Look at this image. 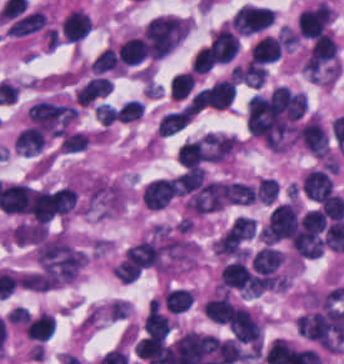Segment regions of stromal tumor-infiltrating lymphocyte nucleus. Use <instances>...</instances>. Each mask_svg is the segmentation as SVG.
Segmentation results:
<instances>
[{"label": "stromal tumor-infiltrating lymphocyte nucleus", "instance_id": "bc302bb0", "mask_svg": "<svg viewBox=\"0 0 344 364\" xmlns=\"http://www.w3.org/2000/svg\"><path fill=\"white\" fill-rule=\"evenodd\" d=\"M299 206L286 202L274 208L264 223L260 234L267 245L289 240L296 226Z\"/></svg>", "mask_w": 344, "mask_h": 364}, {"label": "stromal tumor-infiltrating lymphocyte nucleus", "instance_id": "52c7bb5b", "mask_svg": "<svg viewBox=\"0 0 344 364\" xmlns=\"http://www.w3.org/2000/svg\"><path fill=\"white\" fill-rule=\"evenodd\" d=\"M333 13L327 3L319 2L302 10L297 31L302 38H315L325 32Z\"/></svg>", "mask_w": 344, "mask_h": 364}, {"label": "stromal tumor-infiltrating lymphocyte nucleus", "instance_id": "3290ff9b", "mask_svg": "<svg viewBox=\"0 0 344 364\" xmlns=\"http://www.w3.org/2000/svg\"><path fill=\"white\" fill-rule=\"evenodd\" d=\"M220 286L242 294H255V284L250 268L243 260H235L223 265Z\"/></svg>", "mask_w": 344, "mask_h": 364}, {"label": "stromal tumor-infiltrating lymphocyte nucleus", "instance_id": "abfb95fc", "mask_svg": "<svg viewBox=\"0 0 344 364\" xmlns=\"http://www.w3.org/2000/svg\"><path fill=\"white\" fill-rule=\"evenodd\" d=\"M298 137L303 147L314 156L323 158L328 156V139L318 115H311L299 123Z\"/></svg>", "mask_w": 344, "mask_h": 364}, {"label": "stromal tumor-infiltrating lymphocyte nucleus", "instance_id": "9ea309e8", "mask_svg": "<svg viewBox=\"0 0 344 364\" xmlns=\"http://www.w3.org/2000/svg\"><path fill=\"white\" fill-rule=\"evenodd\" d=\"M233 339L242 344L260 345L261 325L248 311L236 307L229 323Z\"/></svg>", "mask_w": 344, "mask_h": 364}, {"label": "stromal tumor-infiltrating lymphocyte nucleus", "instance_id": "f3e2335f", "mask_svg": "<svg viewBox=\"0 0 344 364\" xmlns=\"http://www.w3.org/2000/svg\"><path fill=\"white\" fill-rule=\"evenodd\" d=\"M122 264L131 270L140 271L160 265V246L153 241H139L126 250Z\"/></svg>", "mask_w": 344, "mask_h": 364}, {"label": "stromal tumor-infiltrating lymphocyte nucleus", "instance_id": "4f13568d", "mask_svg": "<svg viewBox=\"0 0 344 364\" xmlns=\"http://www.w3.org/2000/svg\"><path fill=\"white\" fill-rule=\"evenodd\" d=\"M175 193L173 177L154 179L141 191L140 198L144 207L150 211H158L167 205Z\"/></svg>", "mask_w": 344, "mask_h": 364}, {"label": "stromal tumor-infiltrating lymphocyte nucleus", "instance_id": "2a367800", "mask_svg": "<svg viewBox=\"0 0 344 364\" xmlns=\"http://www.w3.org/2000/svg\"><path fill=\"white\" fill-rule=\"evenodd\" d=\"M256 232L253 217L237 216L219 237L223 250H236L249 241Z\"/></svg>", "mask_w": 344, "mask_h": 364}, {"label": "stromal tumor-infiltrating lymphocyte nucleus", "instance_id": "4803ca6d", "mask_svg": "<svg viewBox=\"0 0 344 364\" xmlns=\"http://www.w3.org/2000/svg\"><path fill=\"white\" fill-rule=\"evenodd\" d=\"M210 41L214 63H228L239 45L237 35L224 23L210 34Z\"/></svg>", "mask_w": 344, "mask_h": 364}, {"label": "stromal tumor-infiltrating lymphocyte nucleus", "instance_id": "4245b91a", "mask_svg": "<svg viewBox=\"0 0 344 364\" xmlns=\"http://www.w3.org/2000/svg\"><path fill=\"white\" fill-rule=\"evenodd\" d=\"M61 31L65 40L79 42L90 32V18L79 9H71L61 21Z\"/></svg>", "mask_w": 344, "mask_h": 364}, {"label": "stromal tumor-infiltrating lymphocyte nucleus", "instance_id": "4c9ddf68", "mask_svg": "<svg viewBox=\"0 0 344 364\" xmlns=\"http://www.w3.org/2000/svg\"><path fill=\"white\" fill-rule=\"evenodd\" d=\"M301 186L308 198L319 202L330 193L333 182L325 170L312 169L303 177Z\"/></svg>", "mask_w": 344, "mask_h": 364}, {"label": "stromal tumor-infiltrating lymphocyte nucleus", "instance_id": "2761f720", "mask_svg": "<svg viewBox=\"0 0 344 364\" xmlns=\"http://www.w3.org/2000/svg\"><path fill=\"white\" fill-rule=\"evenodd\" d=\"M202 308L205 317L209 321L223 325L229 322L235 309L228 293L224 291L205 300Z\"/></svg>", "mask_w": 344, "mask_h": 364}, {"label": "stromal tumor-infiltrating lymphocyte nucleus", "instance_id": "3c572f05", "mask_svg": "<svg viewBox=\"0 0 344 364\" xmlns=\"http://www.w3.org/2000/svg\"><path fill=\"white\" fill-rule=\"evenodd\" d=\"M279 58L278 45L274 37L263 35L250 46V61L268 63Z\"/></svg>", "mask_w": 344, "mask_h": 364}, {"label": "stromal tumor-infiltrating lymphocyte nucleus", "instance_id": "42bb06b2", "mask_svg": "<svg viewBox=\"0 0 344 364\" xmlns=\"http://www.w3.org/2000/svg\"><path fill=\"white\" fill-rule=\"evenodd\" d=\"M283 261L278 251L271 247H264L250 257V268L254 272L266 275L274 272Z\"/></svg>", "mask_w": 344, "mask_h": 364}, {"label": "stromal tumor-infiltrating lymphocyte nucleus", "instance_id": "9e4306bb", "mask_svg": "<svg viewBox=\"0 0 344 364\" xmlns=\"http://www.w3.org/2000/svg\"><path fill=\"white\" fill-rule=\"evenodd\" d=\"M50 314L39 312L31 318L25 329V337L31 341H45L53 330Z\"/></svg>", "mask_w": 344, "mask_h": 364}, {"label": "stromal tumor-infiltrating lymphocyte nucleus", "instance_id": "04cf8593", "mask_svg": "<svg viewBox=\"0 0 344 364\" xmlns=\"http://www.w3.org/2000/svg\"><path fill=\"white\" fill-rule=\"evenodd\" d=\"M224 203L229 205H249L255 197L250 185L232 181L222 184Z\"/></svg>", "mask_w": 344, "mask_h": 364}, {"label": "stromal tumor-infiltrating lymphocyte nucleus", "instance_id": "e9af9c67", "mask_svg": "<svg viewBox=\"0 0 344 364\" xmlns=\"http://www.w3.org/2000/svg\"><path fill=\"white\" fill-rule=\"evenodd\" d=\"M144 54V46L137 36L126 38L116 51L118 61L125 66H135Z\"/></svg>", "mask_w": 344, "mask_h": 364}, {"label": "stromal tumor-infiltrating lymphocyte nucleus", "instance_id": "782c7336", "mask_svg": "<svg viewBox=\"0 0 344 364\" xmlns=\"http://www.w3.org/2000/svg\"><path fill=\"white\" fill-rule=\"evenodd\" d=\"M191 120V115L184 108L169 112L159 118L158 134L170 136L185 127Z\"/></svg>", "mask_w": 344, "mask_h": 364}, {"label": "stromal tumor-infiltrating lymphocyte nucleus", "instance_id": "cac63f63", "mask_svg": "<svg viewBox=\"0 0 344 364\" xmlns=\"http://www.w3.org/2000/svg\"><path fill=\"white\" fill-rule=\"evenodd\" d=\"M89 67L95 74H121V64L112 48L100 51Z\"/></svg>", "mask_w": 344, "mask_h": 364}, {"label": "stromal tumor-infiltrating lymphocyte nucleus", "instance_id": "2e467ee5", "mask_svg": "<svg viewBox=\"0 0 344 364\" xmlns=\"http://www.w3.org/2000/svg\"><path fill=\"white\" fill-rule=\"evenodd\" d=\"M205 150L203 143L200 141L184 142L177 153L178 163L186 169H192L198 166L204 159Z\"/></svg>", "mask_w": 344, "mask_h": 364}, {"label": "stromal tumor-infiltrating lymphocyte nucleus", "instance_id": "7eef579d", "mask_svg": "<svg viewBox=\"0 0 344 364\" xmlns=\"http://www.w3.org/2000/svg\"><path fill=\"white\" fill-rule=\"evenodd\" d=\"M163 300L167 309L173 314H181L189 309L193 302L191 291L183 289H169L165 291Z\"/></svg>", "mask_w": 344, "mask_h": 364}, {"label": "stromal tumor-infiltrating lymphocyte nucleus", "instance_id": "c26a33f6", "mask_svg": "<svg viewBox=\"0 0 344 364\" xmlns=\"http://www.w3.org/2000/svg\"><path fill=\"white\" fill-rule=\"evenodd\" d=\"M194 82V73L189 71L172 77L168 85L169 97L180 101L190 92Z\"/></svg>", "mask_w": 344, "mask_h": 364}, {"label": "stromal tumor-infiltrating lymphocyte nucleus", "instance_id": "3e0999b9", "mask_svg": "<svg viewBox=\"0 0 344 364\" xmlns=\"http://www.w3.org/2000/svg\"><path fill=\"white\" fill-rule=\"evenodd\" d=\"M319 211L329 220L344 216V199L337 194H329L320 204Z\"/></svg>", "mask_w": 344, "mask_h": 364}, {"label": "stromal tumor-infiltrating lymphocyte nucleus", "instance_id": "a0a3295f", "mask_svg": "<svg viewBox=\"0 0 344 364\" xmlns=\"http://www.w3.org/2000/svg\"><path fill=\"white\" fill-rule=\"evenodd\" d=\"M279 185L273 179H259L254 194L263 205H270L278 196Z\"/></svg>", "mask_w": 344, "mask_h": 364}, {"label": "stromal tumor-infiltrating lymphocyte nucleus", "instance_id": "b6af03f8", "mask_svg": "<svg viewBox=\"0 0 344 364\" xmlns=\"http://www.w3.org/2000/svg\"><path fill=\"white\" fill-rule=\"evenodd\" d=\"M142 113L141 101L137 98H130L121 106L116 108L115 121L118 122H130L140 117Z\"/></svg>", "mask_w": 344, "mask_h": 364}, {"label": "stromal tumor-infiltrating lymphocyte nucleus", "instance_id": "6c763739", "mask_svg": "<svg viewBox=\"0 0 344 364\" xmlns=\"http://www.w3.org/2000/svg\"><path fill=\"white\" fill-rule=\"evenodd\" d=\"M214 52L211 46L202 47L195 55L190 67L195 73H206L213 68Z\"/></svg>", "mask_w": 344, "mask_h": 364}, {"label": "stromal tumor-infiltrating lymphocyte nucleus", "instance_id": "fa64b396", "mask_svg": "<svg viewBox=\"0 0 344 364\" xmlns=\"http://www.w3.org/2000/svg\"><path fill=\"white\" fill-rule=\"evenodd\" d=\"M116 108L110 103H96L94 114L100 126H107L114 121Z\"/></svg>", "mask_w": 344, "mask_h": 364}, {"label": "stromal tumor-infiltrating lymphocyte nucleus", "instance_id": "21d57d70", "mask_svg": "<svg viewBox=\"0 0 344 364\" xmlns=\"http://www.w3.org/2000/svg\"><path fill=\"white\" fill-rule=\"evenodd\" d=\"M5 320L24 327L29 322V314L22 306H15L7 313Z\"/></svg>", "mask_w": 344, "mask_h": 364}]
</instances>
